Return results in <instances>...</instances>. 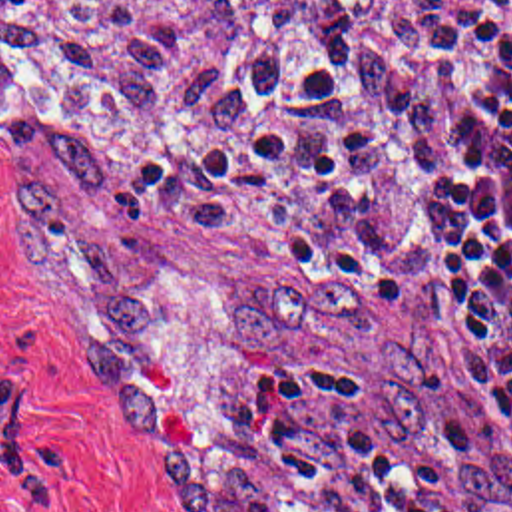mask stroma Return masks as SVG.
Returning <instances> with one entry per match:
<instances>
[{
  "mask_svg": "<svg viewBox=\"0 0 512 512\" xmlns=\"http://www.w3.org/2000/svg\"><path fill=\"white\" fill-rule=\"evenodd\" d=\"M314 1L346 31L330 1ZM511 3L465 0L433 83L461 35ZM346 69L376 139L422 191V205L414 227L392 244H344L338 264L376 314L424 318L433 312L443 338V372L433 390L431 444L406 442L388 428L374 390L334 342L316 336L304 350L280 354L226 338L228 310L240 296L306 288L304 270L278 246L234 232L169 227L127 195L165 268L155 310L137 338V380L159 426V444L183 436L212 412L246 404L268 370L314 360L354 390L398 468L416 477L439 511L512 512V448L439 300L426 125L414 135H394L356 65L348 31ZM13 185L65 199L81 195L55 173L11 161L0 135V512H175L149 466L159 444L135 448L123 420L85 378L83 358L105 336L73 256L53 232L13 207Z\"/></svg>",
  "mask_w": 512,
  "mask_h": 512,
  "instance_id": "obj_1",
  "label": "stroma"
}]
</instances>
